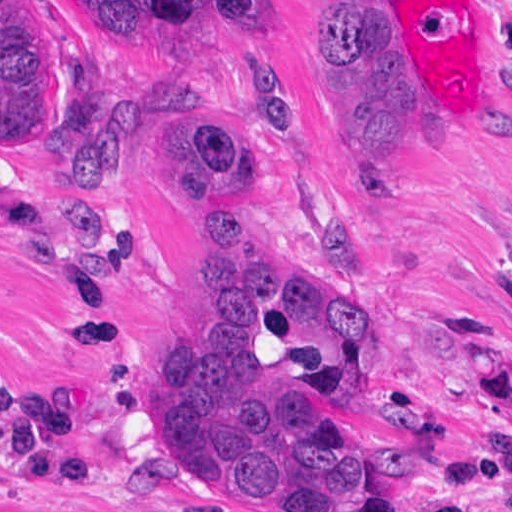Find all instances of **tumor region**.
I'll list each match as a JSON object with an SVG mask.
<instances>
[{
	"instance_id": "1",
	"label": "tumor region",
	"mask_w": 512,
	"mask_h": 512,
	"mask_svg": "<svg viewBox=\"0 0 512 512\" xmlns=\"http://www.w3.org/2000/svg\"><path fill=\"white\" fill-rule=\"evenodd\" d=\"M83 28L156 55L217 52L225 30L257 33L265 0H72ZM322 80L339 132L375 173L415 121L380 74V0H327ZM251 99L273 135H294L292 102ZM171 147L162 176L187 188L224 278V305L165 349L149 377L163 441L159 475L199 495L264 512H366L373 468L332 404L368 374L369 343L350 314L323 328L317 288L282 275L254 229V164L226 99L185 84L159 96ZM1 154L33 146L53 175L102 188L135 153V122L112 105L94 59L52 33L42 0H0ZM41 202L71 230L118 253L129 222ZM512 296V282L510 284Z\"/></svg>"
}]
</instances>
